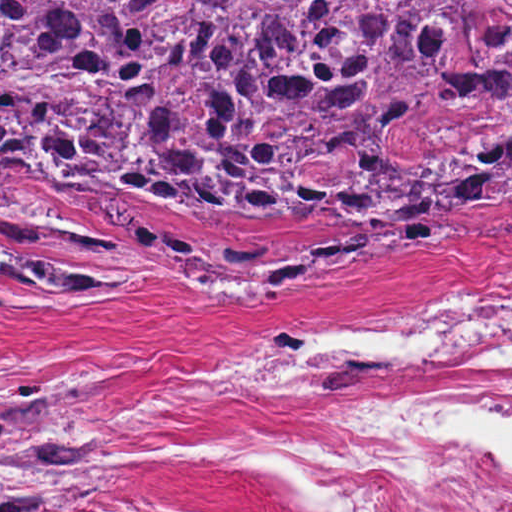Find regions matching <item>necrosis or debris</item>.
<instances>
[{
	"instance_id": "necrosis-or-debris-1",
	"label": "necrosis or debris",
	"mask_w": 512,
	"mask_h": 512,
	"mask_svg": "<svg viewBox=\"0 0 512 512\" xmlns=\"http://www.w3.org/2000/svg\"><path fill=\"white\" fill-rule=\"evenodd\" d=\"M473 362H512V273H425L326 301L277 325L207 383ZM503 409L496 398L382 401L313 437L308 481L334 512H512V464L446 423Z\"/></svg>"
}]
</instances>
